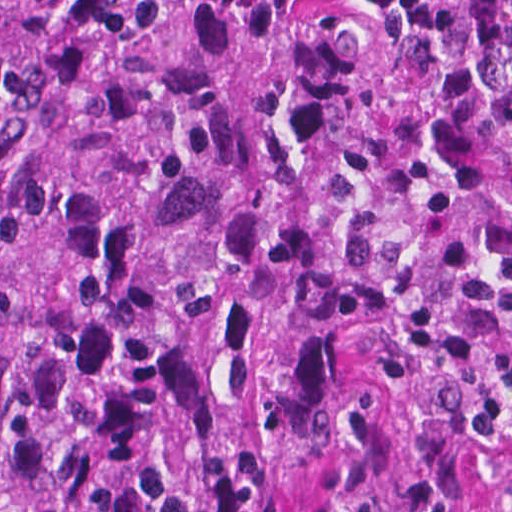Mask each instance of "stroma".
Segmentation results:
<instances>
[{"mask_svg":"<svg viewBox=\"0 0 512 512\" xmlns=\"http://www.w3.org/2000/svg\"><path fill=\"white\" fill-rule=\"evenodd\" d=\"M423 512H512V485L425 486Z\"/></svg>","mask_w":512,"mask_h":512,"instance_id":"35a3bbf8","label":"stroma"}]
</instances>
